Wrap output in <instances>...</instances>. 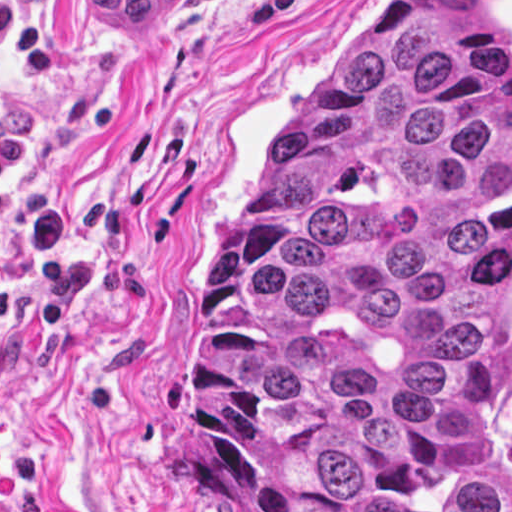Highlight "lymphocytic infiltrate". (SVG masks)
<instances>
[{
    "label": "lymphocytic infiltrate",
    "mask_w": 512,
    "mask_h": 512,
    "mask_svg": "<svg viewBox=\"0 0 512 512\" xmlns=\"http://www.w3.org/2000/svg\"><path fill=\"white\" fill-rule=\"evenodd\" d=\"M238 0H202L203 5H233ZM0 49L12 59V72L26 87L43 84L53 73V43L31 17L7 0H0ZM34 127L30 112L21 108L0 116V222L5 217L4 183L31 157Z\"/></svg>",
    "instance_id": "f902f5d3"
}]
</instances>
